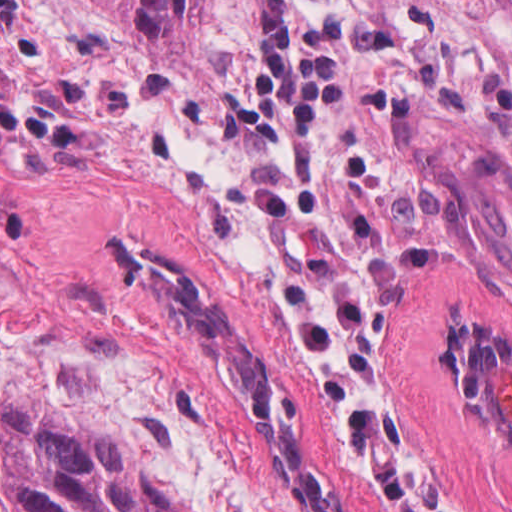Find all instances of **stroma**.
<instances>
[{
    "label": "stroma",
    "instance_id": "stroma-1",
    "mask_svg": "<svg viewBox=\"0 0 512 512\" xmlns=\"http://www.w3.org/2000/svg\"><path fill=\"white\" fill-rule=\"evenodd\" d=\"M315 512H386L363 403L429 512H512V435L456 386V325L512 341V0H286L348 60L305 153L231 111L260 0L196 44L114 0H19Z\"/></svg>",
    "mask_w": 512,
    "mask_h": 512
}]
</instances>
